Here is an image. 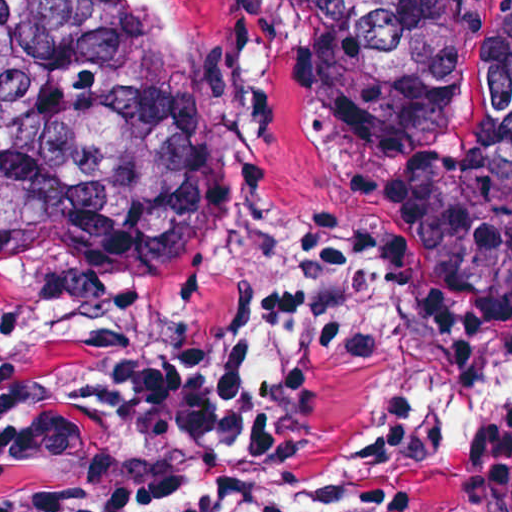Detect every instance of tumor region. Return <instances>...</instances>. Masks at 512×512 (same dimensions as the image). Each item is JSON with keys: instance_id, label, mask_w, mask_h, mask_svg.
I'll list each match as a JSON object with an SVG mask.
<instances>
[{"instance_id": "tumor-region-1", "label": "tumor region", "mask_w": 512, "mask_h": 512, "mask_svg": "<svg viewBox=\"0 0 512 512\" xmlns=\"http://www.w3.org/2000/svg\"><path fill=\"white\" fill-rule=\"evenodd\" d=\"M297 20L360 97L380 159L458 91V0H237ZM215 82L140 41L136 0H0V333L25 317H111L245 341L291 281L239 215L172 170L144 116ZM404 253L512 325V0L463 141L385 179ZM242 378V363L216 371ZM307 434L342 455L357 512H396L415 448L373 443L302 391Z\"/></svg>"}]
</instances>
